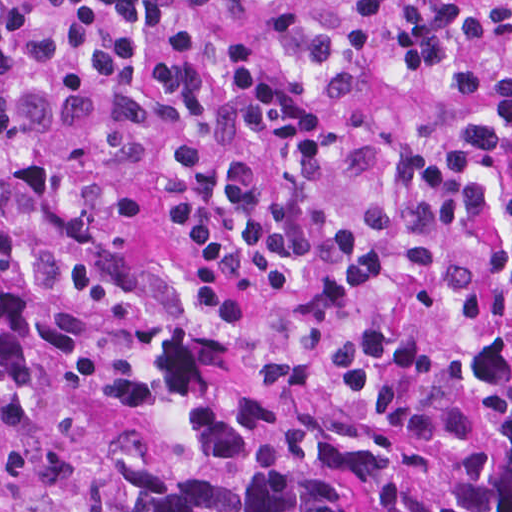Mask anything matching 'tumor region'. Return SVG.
I'll return each mask as SVG.
<instances>
[{
	"mask_svg": "<svg viewBox=\"0 0 512 512\" xmlns=\"http://www.w3.org/2000/svg\"><path fill=\"white\" fill-rule=\"evenodd\" d=\"M0 512H512V267L291 190H0Z\"/></svg>",
	"mask_w": 512,
	"mask_h": 512,
	"instance_id": "e687c5a6",
	"label": "tumor region"
}]
</instances>
